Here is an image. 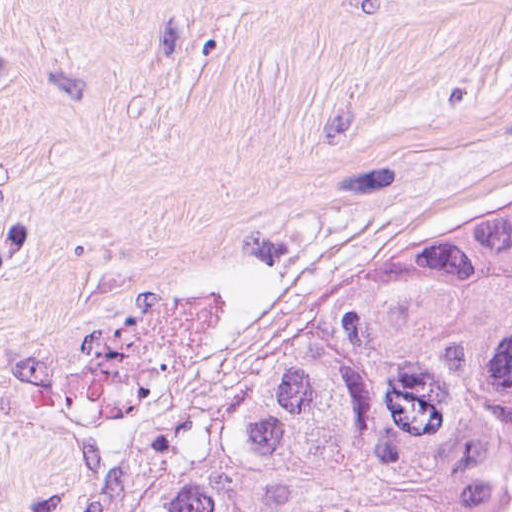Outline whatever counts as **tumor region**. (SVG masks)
<instances>
[{"mask_svg":"<svg viewBox=\"0 0 512 512\" xmlns=\"http://www.w3.org/2000/svg\"><path fill=\"white\" fill-rule=\"evenodd\" d=\"M124 512H512V180L196 399Z\"/></svg>","mask_w":512,"mask_h":512,"instance_id":"e687c5a6","label":"tumor region"}]
</instances>
